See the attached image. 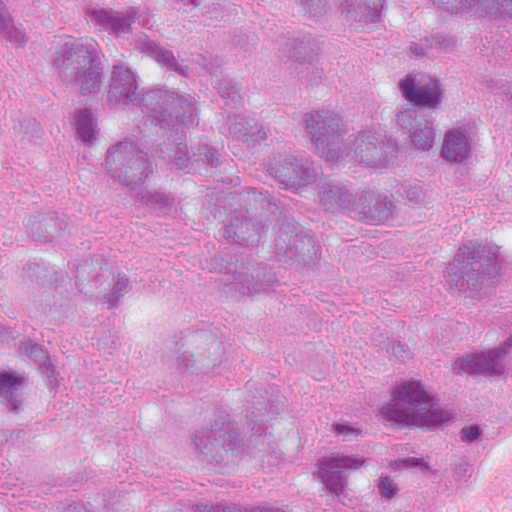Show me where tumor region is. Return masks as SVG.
Here are the masks:
<instances>
[{"label":"tumor region","instance_id":"1","mask_svg":"<svg viewBox=\"0 0 512 512\" xmlns=\"http://www.w3.org/2000/svg\"><path fill=\"white\" fill-rule=\"evenodd\" d=\"M33 0H0V44ZM66 133L153 206L223 293L176 339L62 177L0 206V512H136L68 457L85 317L127 347L175 475L152 512H360L444 380L427 363L283 379L274 317L358 242L425 261L456 367L512 341V0H87L49 42Z\"/></svg>","mask_w":512,"mask_h":512}]
</instances>
